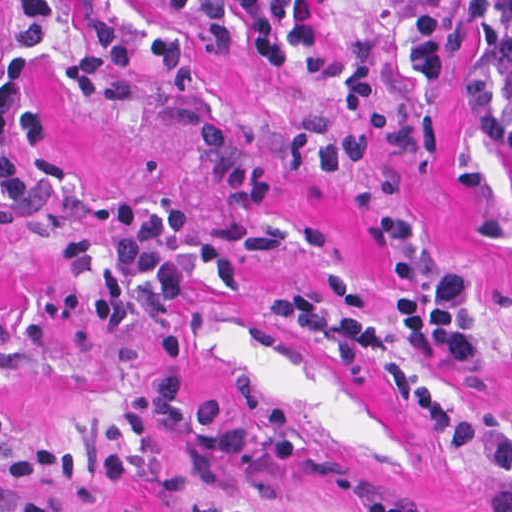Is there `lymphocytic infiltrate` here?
Instances as JSON below:
<instances>
[{
	"instance_id": "lymphocytic-infiltrate-1",
	"label": "lymphocytic infiltrate",
	"mask_w": 512,
	"mask_h": 512,
	"mask_svg": "<svg viewBox=\"0 0 512 512\" xmlns=\"http://www.w3.org/2000/svg\"><path fill=\"white\" fill-rule=\"evenodd\" d=\"M167 15L192 22L138 35L96 15H80L82 55L68 81L85 98L105 103L127 98L142 80L140 65L168 87L194 90L215 60L259 58L281 80L334 94V110L291 120L276 143L240 136L217 124L195 130L206 170L226 203L239 210L267 206L279 171L342 173L356 165L418 145L409 121L388 109L382 80L348 59L306 66L304 51L320 46L317 16L296 0H164ZM410 21L432 55L447 91L462 105L484 113H512V0H407ZM60 15L53 0H0V223H40L68 214L74 189L46 151L52 109L38 82V66L57 48ZM184 206L151 209L138 199H112L92 213L94 224L118 236L111 257L70 240L66 254L75 272L99 275L91 309L102 334H116L138 306L142 288L163 301L189 290L183 263L214 277L227 292L242 288L233 252L215 240L182 242L190 217ZM372 237L390 254L395 303L381 315L365 309L355 275L329 273L330 298L322 303L297 292L269 293L265 306L282 330L329 352L347 370L390 356L409 343L418 354L457 363L481 358V339L471 309V281L461 268L429 266L408 218L382 214ZM12 325L0 320V355ZM407 406L426 416L447 449L509 485L483 494L484 512H512V434L470 423L452 404L405 367L390 370ZM8 408L0 404V478L19 486V512H58L39 479L75 481L79 459L61 441L45 439L14 458L3 447ZM125 431L140 450L112 448L98 468L101 486H125L153 468L170 465L162 425L191 439L214 469L250 454L260 440L255 427L223 423V403L207 398L187 414L177 377L139 386L122 409ZM365 512H408L381 496L363 493Z\"/></svg>"
}]
</instances>
